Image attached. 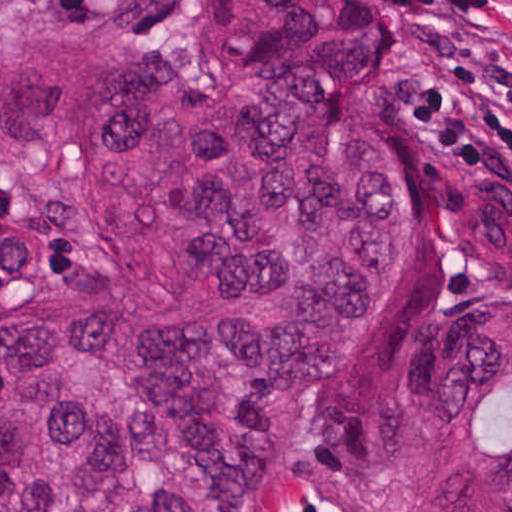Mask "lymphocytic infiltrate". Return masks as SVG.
I'll list each match as a JSON object with an SVG mask.
<instances>
[{"instance_id": "obj_1", "label": "lymphocytic infiltrate", "mask_w": 512, "mask_h": 512, "mask_svg": "<svg viewBox=\"0 0 512 512\" xmlns=\"http://www.w3.org/2000/svg\"><path fill=\"white\" fill-rule=\"evenodd\" d=\"M53 16L105 14L131 37H159L187 0H40ZM418 44L395 91L403 136L451 161L512 170V0H383Z\"/></svg>"}]
</instances>
